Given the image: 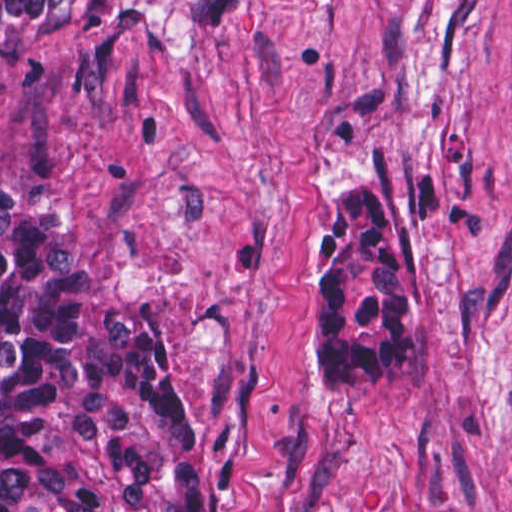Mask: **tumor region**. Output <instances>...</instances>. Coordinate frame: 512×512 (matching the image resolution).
I'll return each mask as SVG.
<instances>
[{"mask_svg": "<svg viewBox=\"0 0 512 512\" xmlns=\"http://www.w3.org/2000/svg\"><path fill=\"white\" fill-rule=\"evenodd\" d=\"M245 0H0L17 72L59 29L124 14L196 27ZM333 235L304 292L328 396L385 376L424 340L427 312L389 188L320 182ZM205 425L164 376V318L111 302L59 208L0 175V512H195Z\"/></svg>", "mask_w": 512, "mask_h": 512, "instance_id": "e687c5a6", "label": "tumor region"}]
</instances>
